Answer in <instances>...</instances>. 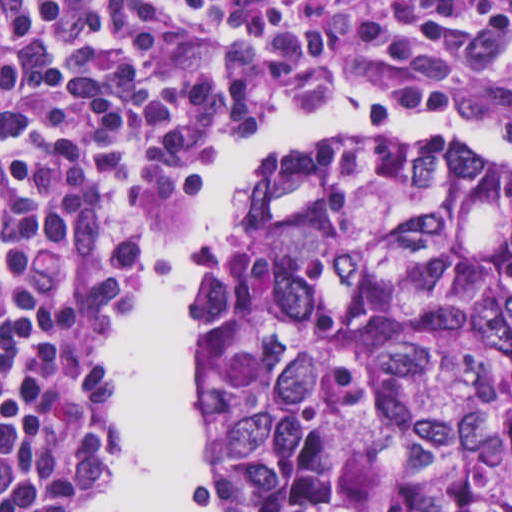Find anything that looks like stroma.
<instances>
[{
    "instance_id": "obj_1",
    "label": "stroma",
    "mask_w": 512,
    "mask_h": 512,
    "mask_svg": "<svg viewBox=\"0 0 512 512\" xmlns=\"http://www.w3.org/2000/svg\"><path fill=\"white\" fill-rule=\"evenodd\" d=\"M0 1H512V0H0ZM324 102L341 103V104L348 106L353 111H355V109L352 107V105L349 103V101L343 95H331ZM472 127H474L475 129H477L478 131H480L481 133L485 134L488 137H509L503 133H500L498 131L490 129L486 126H472ZM226 150H227V148L215 153L210 158H208L206 167L212 163L220 162V160ZM505 157L512 163V160L509 157H507L506 155H505ZM259 163L260 162L250 165V166L246 167L245 169H243L241 172H239L227 192V205H226V211H225V228H224L223 236L220 241V246H219L218 251L225 249L228 246V244L231 242V237H232V190H233L234 183L236 181H238L240 178H242L247 172H249L253 167H255ZM200 271L193 278L188 290L190 289V287L196 280L197 276L200 274ZM145 277H146V275H145ZM144 281H145V278L142 281V283L139 285V287L137 288L135 293L132 295V297L126 304V306L123 308V310L121 311L119 316L122 315V313L125 310V308L127 307V305L130 303V301L133 299V297L136 295V293L139 291V289L144 284ZM188 290H187V292H188ZM110 328L108 330V333L110 331ZM108 333H107V335H108ZM106 360H107V358H106ZM107 366H108V362H107ZM108 393L113 398L111 388H110L109 366H108ZM188 394H189L191 411H192V415H193V419H194L195 438H196V442H197V446H198V384H197L196 377H195V365H194V361H193V335L191 332L189 334V342H188ZM120 434H121V430H120V426H119L115 474H114V480L112 482V485L115 481L117 465H118V446H119ZM205 465H206V463H205ZM206 482H207L213 503H214L217 511L222 512L216 502V497H215V493H214V489H213V485L211 482V478H210V474H209L207 465H206ZM112 485H111V487H112ZM111 487L109 489H107L105 492H103L101 495L95 497L93 499V502L95 500L99 499L100 497H102L106 492H108L111 489Z\"/></svg>"
}]
</instances>
